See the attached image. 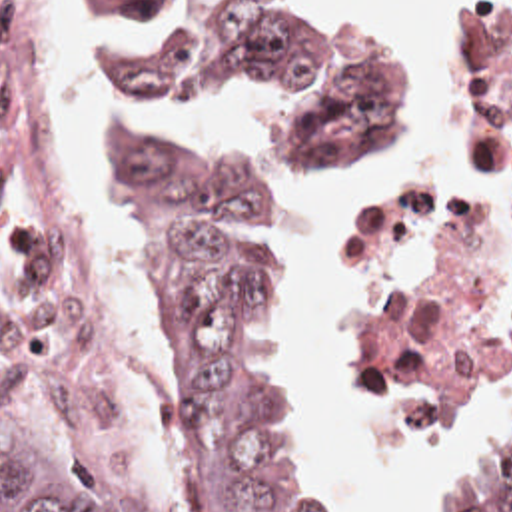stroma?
Segmentation results:
<instances>
[{
    "mask_svg": "<svg viewBox=\"0 0 512 512\" xmlns=\"http://www.w3.org/2000/svg\"><path fill=\"white\" fill-rule=\"evenodd\" d=\"M72 10V202L78 232L86 250L104 280V240L98 204L86 184V78L80 62V20L76 0H68ZM469 0H461L447 32V108L459 60ZM419 76V36L409 50L397 54V92L387 116L373 126L347 154L351 156L375 130L387 124L393 114L413 96ZM439 150L419 162L383 174L355 208L351 230L333 266V318L335 328L347 348L353 375L367 393L383 405L413 421L439 423L447 429L461 457L451 475L423 493L413 512H449L461 489L499 451L493 449L485 433V409L477 415H459L429 399L415 370L385 342L367 306V262L373 238L397 220L427 188ZM345 156V158H347ZM343 158V160H345ZM343 160L317 174H291L295 192L275 196V268L291 312V350L307 379L315 449L325 481L341 501L345 512L355 511V485L349 475V451L337 419V389L327 362L317 344V318L313 298L305 286V256L301 246V194L323 180ZM512 372V354L503 368L501 383ZM0 374L46 427V431L82 459L92 471L108 481L136 511L138 503L128 477L126 461H96L72 447L50 417L24 358L0 320ZM501 387V385H499Z\"/></svg>",
    "mask_w": 512,
    "mask_h": 512,
    "instance_id": "35a3bbf8",
    "label": "stroma"
}]
</instances>
